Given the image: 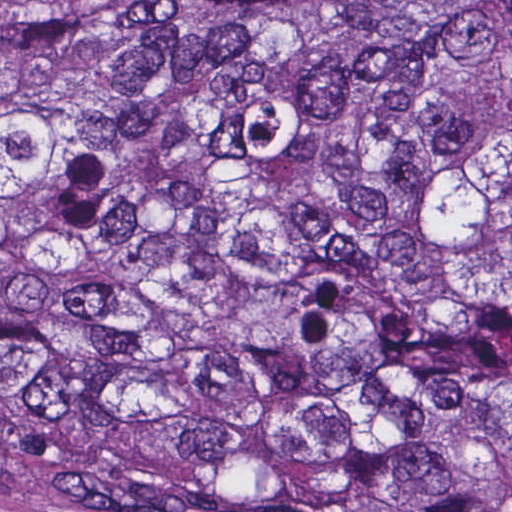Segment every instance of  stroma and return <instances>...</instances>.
I'll use <instances>...</instances> for the list:
<instances>
[{
	"instance_id": "1",
	"label": "stroma",
	"mask_w": 512,
	"mask_h": 512,
	"mask_svg": "<svg viewBox=\"0 0 512 512\" xmlns=\"http://www.w3.org/2000/svg\"><path fill=\"white\" fill-rule=\"evenodd\" d=\"M132 0H0V34L49 8L118 7ZM0 512H153L75 486L33 464L0 465Z\"/></svg>"
}]
</instances>
